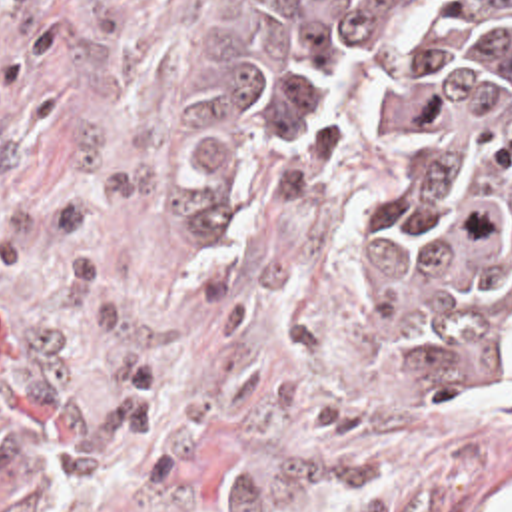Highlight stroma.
Returning <instances> with one entry per match:
<instances>
[{"label": "stroma", "mask_w": 512, "mask_h": 512, "mask_svg": "<svg viewBox=\"0 0 512 512\" xmlns=\"http://www.w3.org/2000/svg\"><path fill=\"white\" fill-rule=\"evenodd\" d=\"M258 0H0V512H480L512 391L450 399L366 287L360 157H214Z\"/></svg>", "instance_id": "obj_1"}]
</instances>
